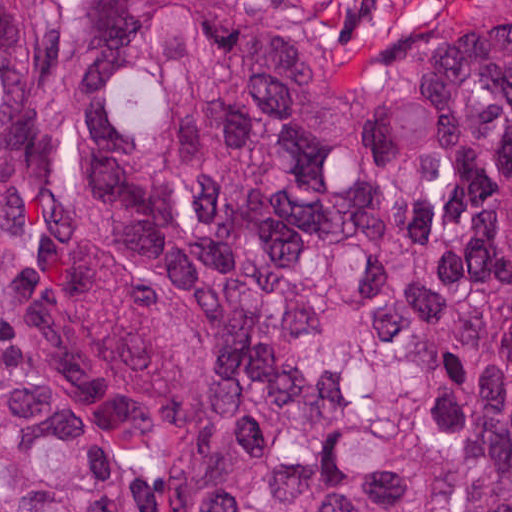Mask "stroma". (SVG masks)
<instances>
[{
  "mask_svg": "<svg viewBox=\"0 0 512 512\" xmlns=\"http://www.w3.org/2000/svg\"><path fill=\"white\" fill-rule=\"evenodd\" d=\"M59 10L67 0H41ZM309 10L350 77L370 85L420 72L453 28L489 0H295ZM422 495L430 512H461L465 483L430 457L422 439Z\"/></svg>",
  "mask_w": 512,
  "mask_h": 512,
  "instance_id": "stroma-1",
  "label": "stroma"
}]
</instances>
